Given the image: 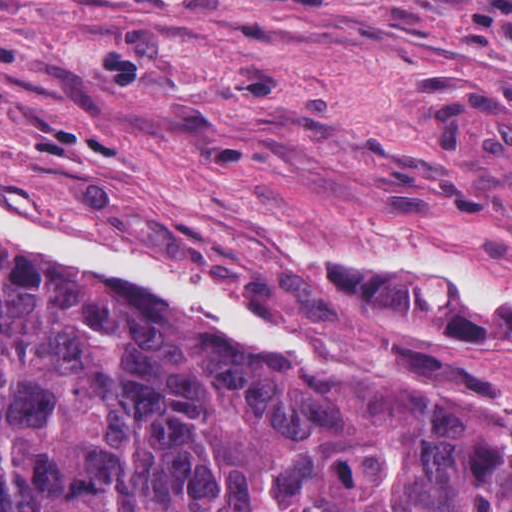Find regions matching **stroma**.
Wrapping results in <instances>:
<instances>
[{
	"mask_svg": "<svg viewBox=\"0 0 512 512\" xmlns=\"http://www.w3.org/2000/svg\"><path fill=\"white\" fill-rule=\"evenodd\" d=\"M0 198L512 409V313L351 262L512 263V0H0Z\"/></svg>",
	"mask_w": 512,
	"mask_h": 512,
	"instance_id": "obj_1",
	"label": "stroma"
}]
</instances>
